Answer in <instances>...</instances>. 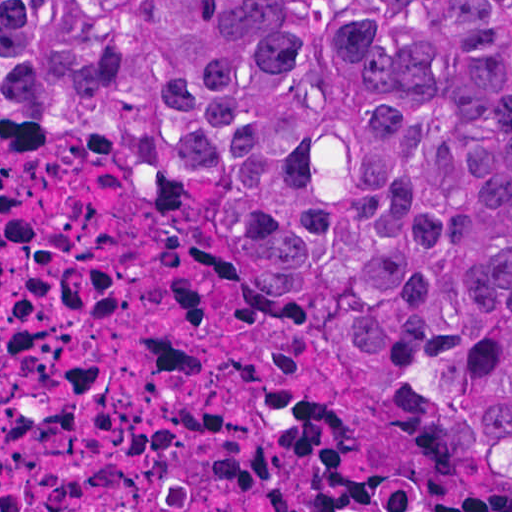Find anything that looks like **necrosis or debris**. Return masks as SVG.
<instances>
[{
  "label": "necrosis or debris",
  "mask_w": 512,
  "mask_h": 512,
  "mask_svg": "<svg viewBox=\"0 0 512 512\" xmlns=\"http://www.w3.org/2000/svg\"><path fill=\"white\" fill-rule=\"evenodd\" d=\"M0 512H512V460L158 163L0 126Z\"/></svg>",
  "instance_id": "obj_1"
}]
</instances>
